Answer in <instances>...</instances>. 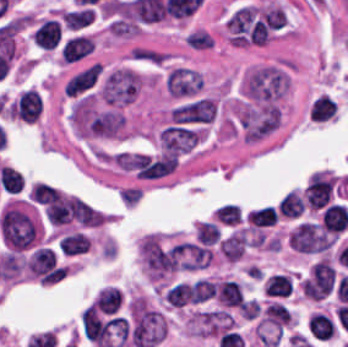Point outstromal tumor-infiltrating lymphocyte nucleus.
I'll use <instances>...</instances> for the list:
<instances>
[{
    "instance_id": "1",
    "label": "stromal tumor-infiltrating lymphocyte nucleus",
    "mask_w": 348,
    "mask_h": 347,
    "mask_svg": "<svg viewBox=\"0 0 348 347\" xmlns=\"http://www.w3.org/2000/svg\"><path fill=\"white\" fill-rule=\"evenodd\" d=\"M4 242L14 251H21L35 238L36 225L24 212L7 205L1 217Z\"/></svg>"
},
{
    "instance_id": "2",
    "label": "stromal tumor-infiltrating lymphocyte nucleus",
    "mask_w": 348,
    "mask_h": 347,
    "mask_svg": "<svg viewBox=\"0 0 348 347\" xmlns=\"http://www.w3.org/2000/svg\"><path fill=\"white\" fill-rule=\"evenodd\" d=\"M332 192V177L315 171L307 184L306 203L310 209H321L331 199Z\"/></svg>"
},
{
    "instance_id": "3",
    "label": "stromal tumor-infiltrating lymphocyte nucleus",
    "mask_w": 348,
    "mask_h": 347,
    "mask_svg": "<svg viewBox=\"0 0 348 347\" xmlns=\"http://www.w3.org/2000/svg\"><path fill=\"white\" fill-rule=\"evenodd\" d=\"M263 290L272 299H287L295 291V283L283 272L268 274L263 282Z\"/></svg>"
},
{
    "instance_id": "4",
    "label": "stromal tumor-infiltrating lymphocyte nucleus",
    "mask_w": 348,
    "mask_h": 347,
    "mask_svg": "<svg viewBox=\"0 0 348 347\" xmlns=\"http://www.w3.org/2000/svg\"><path fill=\"white\" fill-rule=\"evenodd\" d=\"M321 225L334 233L346 230L348 226V207L331 203L321 213Z\"/></svg>"
},
{
    "instance_id": "5",
    "label": "stromal tumor-infiltrating lymphocyte nucleus",
    "mask_w": 348,
    "mask_h": 347,
    "mask_svg": "<svg viewBox=\"0 0 348 347\" xmlns=\"http://www.w3.org/2000/svg\"><path fill=\"white\" fill-rule=\"evenodd\" d=\"M216 295L222 305L243 306L245 297L241 287L235 280H222L217 283Z\"/></svg>"
},
{
    "instance_id": "6",
    "label": "stromal tumor-infiltrating lymphocyte nucleus",
    "mask_w": 348,
    "mask_h": 347,
    "mask_svg": "<svg viewBox=\"0 0 348 347\" xmlns=\"http://www.w3.org/2000/svg\"><path fill=\"white\" fill-rule=\"evenodd\" d=\"M308 329L315 339L330 340L334 333L333 323L320 312H313L308 319Z\"/></svg>"
},
{
    "instance_id": "7",
    "label": "stromal tumor-infiltrating lymphocyte nucleus",
    "mask_w": 348,
    "mask_h": 347,
    "mask_svg": "<svg viewBox=\"0 0 348 347\" xmlns=\"http://www.w3.org/2000/svg\"><path fill=\"white\" fill-rule=\"evenodd\" d=\"M305 199L298 191H291L282 197L279 204V211L283 216L296 218L305 211Z\"/></svg>"
},
{
    "instance_id": "8",
    "label": "stromal tumor-infiltrating lymphocyte nucleus",
    "mask_w": 348,
    "mask_h": 347,
    "mask_svg": "<svg viewBox=\"0 0 348 347\" xmlns=\"http://www.w3.org/2000/svg\"><path fill=\"white\" fill-rule=\"evenodd\" d=\"M252 226H266L277 223L278 215L274 207L251 210L246 218Z\"/></svg>"
},
{
    "instance_id": "9",
    "label": "stromal tumor-infiltrating lymphocyte nucleus",
    "mask_w": 348,
    "mask_h": 347,
    "mask_svg": "<svg viewBox=\"0 0 348 347\" xmlns=\"http://www.w3.org/2000/svg\"><path fill=\"white\" fill-rule=\"evenodd\" d=\"M263 320L282 327L291 321V315L285 307L278 303H271L263 312Z\"/></svg>"
},
{
    "instance_id": "10",
    "label": "stromal tumor-infiltrating lymphocyte nucleus",
    "mask_w": 348,
    "mask_h": 347,
    "mask_svg": "<svg viewBox=\"0 0 348 347\" xmlns=\"http://www.w3.org/2000/svg\"><path fill=\"white\" fill-rule=\"evenodd\" d=\"M214 218L222 223L237 225L242 221V211L240 206L234 203H227L216 209Z\"/></svg>"
},
{
    "instance_id": "11",
    "label": "stromal tumor-infiltrating lymphocyte nucleus",
    "mask_w": 348,
    "mask_h": 347,
    "mask_svg": "<svg viewBox=\"0 0 348 347\" xmlns=\"http://www.w3.org/2000/svg\"><path fill=\"white\" fill-rule=\"evenodd\" d=\"M191 297L190 285L185 283H177L167 290L165 293V301L170 306H178L185 304Z\"/></svg>"
},
{
    "instance_id": "12",
    "label": "stromal tumor-infiltrating lymphocyte nucleus",
    "mask_w": 348,
    "mask_h": 347,
    "mask_svg": "<svg viewBox=\"0 0 348 347\" xmlns=\"http://www.w3.org/2000/svg\"><path fill=\"white\" fill-rule=\"evenodd\" d=\"M196 234L203 245H214L220 241L221 233L215 223L201 222L196 226Z\"/></svg>"
},
{
    "instance_id": "13",
    "label": "stromal tumor-infiltrating lymphocyte nucleus",
    "mask_w": 348,
    "mask_h": 347,
    "mask_svg": "<svg viewBox=\"0 0 348 347\" xmlns=\"http://www.w3.org/2000/svg\"><path fill=\"white\" fill-rule=\"evenodd\" d=\"M119 293H121V290L119 289V290H117Z\"/></svg>"
}]
</instances>
